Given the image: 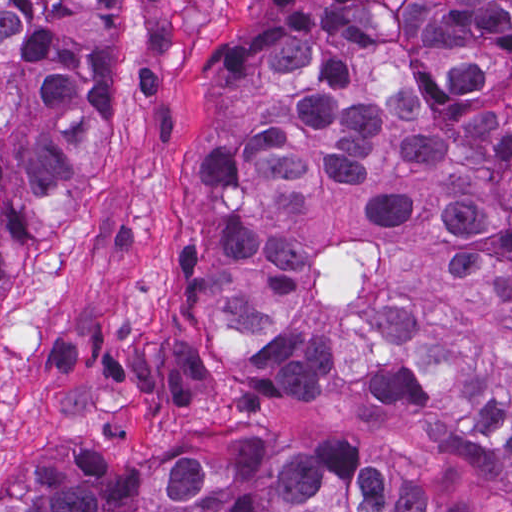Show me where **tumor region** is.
Wrapping results in <instances>:
<instances>
[{
	"instance_id": "1",
	"label": "tumor region",
	"mask_w": 512,
	"mask_h": 512,
	"mask_svg": "<svg viewBox=\"0 0 512 512\" xmlns=\"http://www.w3.org/2000/svg\"><path fill=\"white\" fill-rule=\"evenodd\" d=\"M126 0H0V289L121 103ZM512 0H233L205 66L198 332L265 398L337 383L512 483ZM0 512H471L239 414L14 465Z\"/></svg>"
}]
</instances>
